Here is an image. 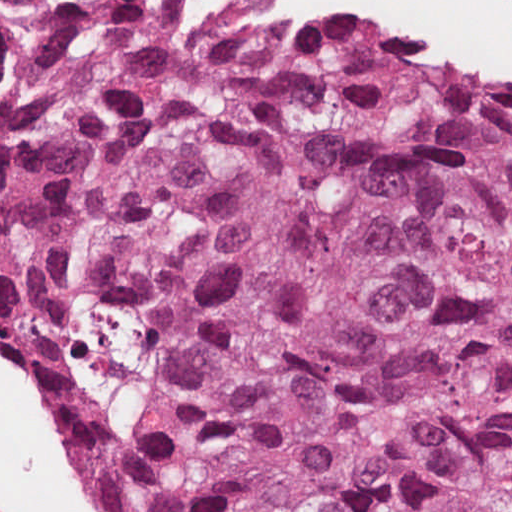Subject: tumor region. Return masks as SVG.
<instances>
[{
    "instance_id": "1",
    "label": "tumor region",
    "mask_w": 512,
    "mask_h": 512,
    "mask_svg": "<svg viewBox=\"0 0 512 512\" xmlns=\"http://www.w3.org/2000/svg\"><path fill=\"white\" fill-rule=\"evenodd\" d=\"M0 364L103 512H512V88L0 1Z\"/></svg>"
}]
</instances>
